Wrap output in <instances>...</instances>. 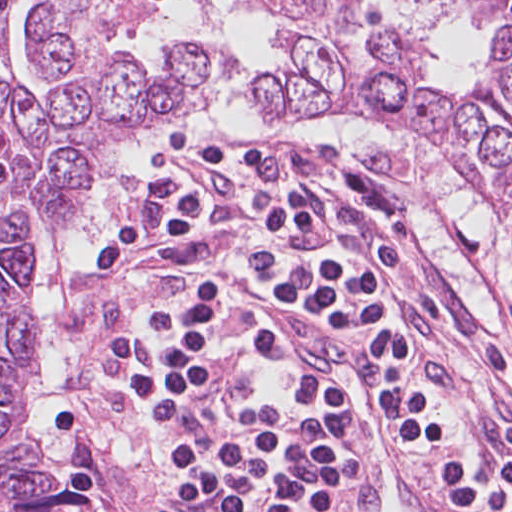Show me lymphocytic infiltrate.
Returning <instances> with one entry per match:
<instances>
[{"label": "lymphocytic infiltrate", "instance_id": "f902f5d3", "mask_svg": "<svg viewBox=\"0 0 512 512\" xmlns=\"http://www.w3.org/2000/svg\"><path fill=\"white\" fill-rule=\"evenodd\" d=\"M416 193L376 154L250 132L197 134L151 173L85 272L104 365L161 453L155 512H358L344 422L260 325L277 298L369 342L384 418L445 512H512V460L411 325L445 318L415 271ZM497 302L498 335L470 346L512 377L510 290Z\"/></svg>", "mask_w": 512, "mask_h": 512}]
</instances>
